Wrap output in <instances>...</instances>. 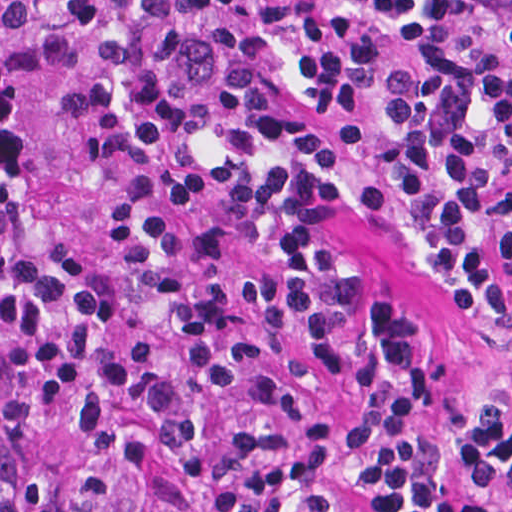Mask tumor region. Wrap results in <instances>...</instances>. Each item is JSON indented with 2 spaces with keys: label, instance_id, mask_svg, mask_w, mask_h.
I'll return each instance as SVG.
<instances>
[{
  "label": "tumor region",
  "instance_id": "obj_1",
  "mask_svg": "<svg viewBox=\"0 0 512 512\" xmlns=\"http://www.w3.org/2000/svg\"><path fill=\"white\" fill-rule=\"evenodd\" d=\"M69 1L0 0V512H183L207 272Z\"/></svg>",
  "mask_w": 512,
  "mask_h": 512
}]
</instances>
